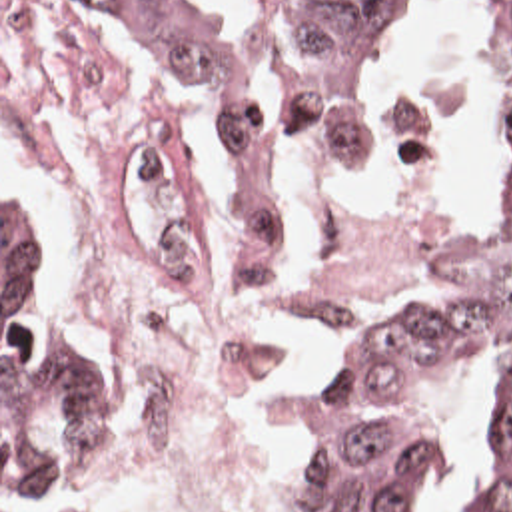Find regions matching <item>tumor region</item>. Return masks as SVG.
<instances>
[{
    "label": "tumor region",
    "instance_id": "obj_1",
    "mask_svg": "<svg viewBox=\"0 0 512 512\" xmlns=\"http://www.w3.org/2000/svg\"><path fill=\"white\" fill-rule=\"evenodd\" d=\"M84 1L206 121L240 273H264L274 225L298 205L282 195V145L228 85L198 3ZM405 5L276 0L300 145L377 147L379 113L355 65ZM489 47L512 101V0H493ZM473 379L485 434L455 512H512V223L491 209L485 249L379 309L339 355L294 458V512H405L469 415ZM120 450L122 401L98 359L56 331L32 215L2 189V494H58Z\"/></svg>",
    "mask_w": 512,
    "mask_h": 512
}]
</instances>
